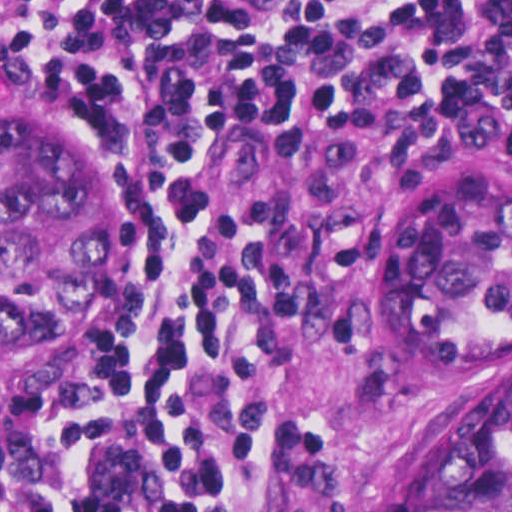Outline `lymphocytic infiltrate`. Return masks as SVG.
Wrapping results in <instances>:
<instances>
[{
  "instance_id": "obj_1",
  "label": "lymphocytic infiltrate",
  "mask_w": 512,
  "mask_h": 512,
  "mask_svg": "<svg viewBox=\"0 0 512 512\" xmlns=\"http://www.w3.org/2000/svg\"><path fill=\"white\" fill-rule=\"evenodd\" d=\"M0 81L110 122L132 205L178 235L156 333L70 389L0 512H258L245 496L248 335L298 297L252 147L412 110L434 144L512 145V0H0Z\"/></svg>"
}]
</instances>
